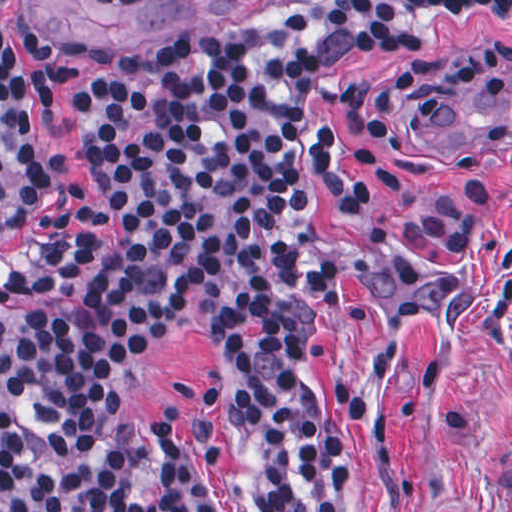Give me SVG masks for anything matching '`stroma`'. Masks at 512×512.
I'll return each instance as SVG.
<instances>
[{
    "instance_id": "35a3bbf8",
    "label": "stroma",
    "mask_w": 512,
    "mask_h": 512,
    "mask_svg": "<svg viewBox=\"0 0 512 512\" xmlns=\"http://www.w3.org/2000/svg\"><path fill=\"white\" fill-rule=\"evenodd\" d=\"M343 0H6L19 57L56 91L37 111L50 199L95 190L73 105L100 67L85 43L146 44L278 23ZM423 50L354 56L325 72L319 105L374 147L375 205L326 234L328 296L308 337V384L333 423L336 512H512V153L438 148L435 98L465 74L512 69V4L416 11ZM132 401L154 446L149 477L96 512H274L273 389L217 307H182L132 341Z\"/></svg>"
}]
</instances>
